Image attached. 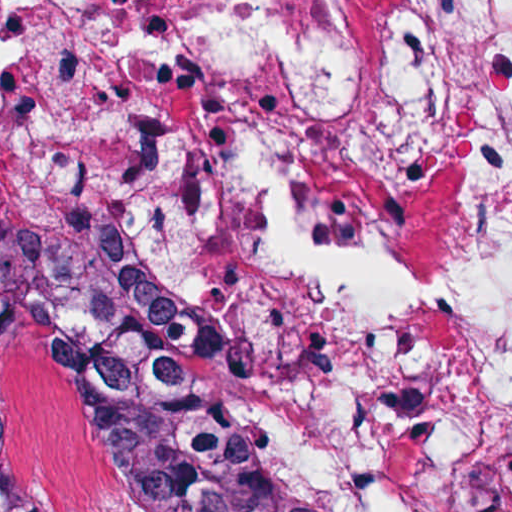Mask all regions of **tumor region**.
<instances>
[{
	"label": "tumor region",
	"mask_w": 512,
	"mask_h": 512,
	"mask_svg": "<svg viewBox=\"0 0 512 512\" xmlns=\"http://www.w3.org/2000/svg\"><path fill=\"white\" fill-rule=\"evenodd\" d=\"M50 320L82 446L121 512H344L318 504L244 410L154 343L80 316L0 270V312ZM0 512H51L10 462L0 432Z\"/></svg>",
	"instance_id": "obj_1"
}]
</instances>
